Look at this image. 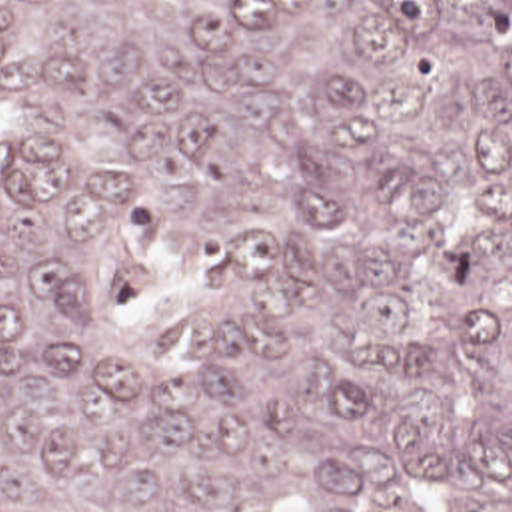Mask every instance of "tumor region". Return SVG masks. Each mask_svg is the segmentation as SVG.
<instances>
[{"label": "tumor region", "mask_w": 512, "mask_h": 512, "mask_svg": "<svg viewBox=\"0 0 512 512\" xmlns=\"http://www.w3.org/2000/svg\"><path fill=\"white\" fill-rule=\"evenodd\" d=\"M0 512H512V0H0Z\"/></svg>", "instance_id": "tumor-region-1"}]
</instances>
